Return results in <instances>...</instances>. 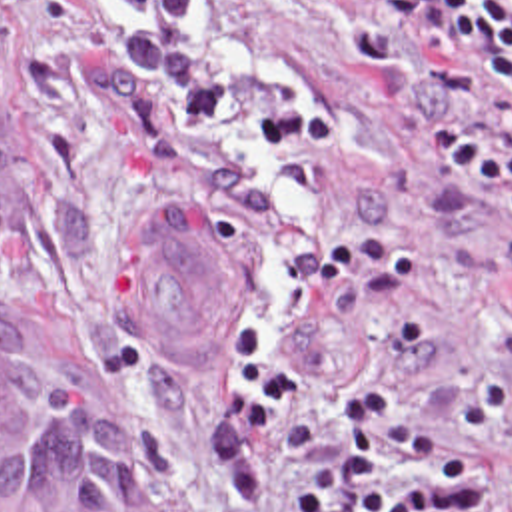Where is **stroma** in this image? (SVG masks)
Instances as JSON below:
<instances>
[{
  "label": "stroma",
  "mask_w": 512,
  "mask_h": 512,
  "mask_svg": "<svg viewBox=\"0 0 512 512\" xmlns=\"http://www.w3.org/2000/svg\"><path fill=\"white\" fill-rule=\"evenodd\" d=\"M1 312L98 424L106 512H512V102L338 0H0ZM182 208L236 344L174 360L116 258Z\"/></svg>",
  "instance_id": "stroma-1"
}]
</instances>
